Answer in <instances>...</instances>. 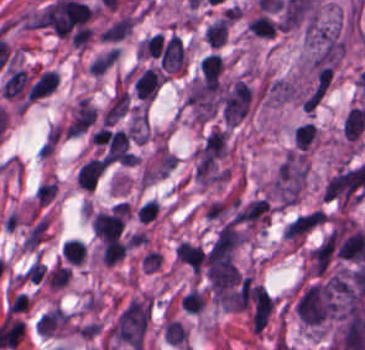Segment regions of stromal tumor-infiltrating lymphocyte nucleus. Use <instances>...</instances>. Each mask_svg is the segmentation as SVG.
Returning <instances> with one entry per match:
<instances>
[{
  "instance_id": "obj_1",
  "label": "stromal tumor-infiltrating lymphocyte nucleus",
  "mask_w": 365,
  "mask_h": 350,
  "mask_svg": "<svg viewBox=\"0 0 365 350\" xmlns=\"http://www.w3.org/2000/svg\"><path fill=\"white\" fill-rule=\"evenodd\" d=\"M123 222L122 210L102 212L92 219L93 233L102 240L119 237Z\"/></svg>"
},
{
  "instance_id": "obj_2",
  "label": "stromal tumor-infiltrating lymphocyte nucleus",
  "mask_w": 365,
  "mask_h": 350,
  "mask_svg": "<svg viewBox=\"0 0 365 350\" xmlns=\"http://www.w3.org/2000/svg\"><path fill=\"white\" fill-rule=\"evenodd\" d=\"M184 66V45L179 36L172 35L167 41L161 56L160 68L176 72Z\"/></svg>"
},
{
  "instance_id": "obj_3",
  "label": "stromal tumor-infiltrating lymphocyte nucleus",
  "mask_w": 365,
  "mask_h": 350,
  "mask_svg": "<svg viewBox=\"0 0 365 350\" xmlns=\"http://www.w3.org/2000/svg\"><path fill=\"white\" fill-rule=\"evenodd\" d=\"M106 169V160L90 159L76 174L77 186L83 190H93Z\"/></svg>"
},
{
  "instance_id": "obj_4",
  "label": "stromal tumor-infiltrating lymphocyte nucleus",
  "mask_w": 365,
  "mask_h": 350,
  "mask_svg": "<svg viewBox=\"0 0 365 350\" xmlns=\"http://www.w3.org/2000/svg\"><path fill=\"white\" fill-rule=\"evenodd\" d=\"M161 82V73L152 68H145L133 84L136 95L142 99H153Z\"/></svg>"
},
{
  "instance_id": "obj_5",
  "label": "stromal tumor-infiltrating lymphocyte nucleus",
  "mask_w": 365,
  "mask_h": 350,
  "mask_svg": "<svg viewBox=\"0 0 365 350\" xmlns=\"http://www.w3.org/2000/svg\"><path fill=\"white\" fill-rule=\"evenodd\" d=\"M176 258L182 261L190 268L199 270L205 260V254L202 249L194 243L180 241L175 248Z\"/></svg>"
},
{
  "instance_id": "obj_6",
  "label": "stromal tumor-infiltrating lymphocyte nucleus",
  "mask_w": 365,
  "mask_h": 350,
  "mask_svg": "<svg viewBox=\"0 0 365 350\" xmlns=\"http://www.w3.org/2000/svg\"><path fill=\"white\" fill-rule=\"evenodd\" d=\"M129 244L118 238H105L102 242V263L113 264L123 258Z\"/></svg>"
},
{
  "instance_id": "obj_7",
  "label": "stromal tumor-infiltrating lymphocyte nucleus",
  "mask_w": 365,
  "mask_h": 350,
  "mask_svg": "<svg viewBox=\"0 0 365 350\" xmlns=\"http://www.w3.org/2000/svg\"><path fill=\"white\" fill-rule=\"evenodd\" d=\"M318 133V127L310 122H303L293 131V144L298 150L304 151L312 145Z\"/></svg>"
},
{
  "instance_id": "obj_8",
  "label": "stromal tumor-infiltrating lymphocyte nucleus",
  "mask_w": 365,
  "mask_h": 350,
  "mask_svg": "<svg viewBox=\"0 0 365 350\" xmlns=\"http://www.w3.org/2000/svg\"><path fill=\"white\" fill-rule=\"evenodd\" d=\"M228 20L222 17L211 25L207 26L204 37L205 40L214 46H221L227 34Z\"/></svg>"
},
{
  "instance_id": "obj_9",
  "label": "stromal tumor-infiltrating lymphocyte nucleus",
  "mask_w": 365,
  "mask_h": 350,
  "mask_svg": "<svg viewBox=\"0 0 365 350\" xmlns=\"http://www.w3.org/2000/svg\"><path fill=\"white\" fill-rule=\"evenodd\" d=\"M62 252L70 262L81 264L86 256V244L78 238H71L64 243Z\"/></svg>"
},
{
  "instance_id": "obj_10",
  "label": "stromal tumor-infiltrating lymphocyte nucleus",
  "mask_w": 365,
  "mask_h": 350,
  "mask_svg": "<svg viewBox=\"0 0 365 350\" xmlns=\"http://www.w3.org/2000/svg\"><path fill=\"white\" fill-rule=\"evenodd\" d=\"M250 30L255 35L274 36L277 29L275 22L265 15H259L248 21Z\"/></svg>"
},
{
  "instance_id": "obj_11",
  "label": "stromal tumor-infiltrating lymphocyte nucleus",
  "mask_w": 365,
  "mask_h": 350,
  "mask_svg": "<svg viewBox=\"0 0 365 350\" xmlns=\"http://www.w3.org/2000/svg\"><path fill=\"white\" fill-rule=\"evenodd\" d=\"M200 68L206 70V71H213V72H220L222 71V63L219 60L218 56L216 53H207L201 63H200Z\"/></svg>"
}]
</instances>
